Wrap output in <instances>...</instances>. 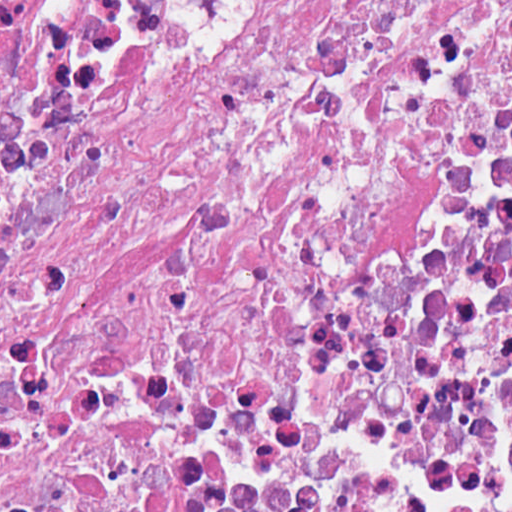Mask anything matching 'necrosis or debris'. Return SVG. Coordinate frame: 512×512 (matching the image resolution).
Segmentation results:
<instances>
[{"label": "necrosis or debris", "mask_w": 512, "mask_h": 512, "mask_svg": "<svg viewBox=\"0 0 512 512\" xmlns=\"http://www.w3.org/2000/svg\"><path fill=\"white\" fill-rule=\"evenodd\" d=\"M0 512H512V1H0Z\"/></svg>", "instance_id": "4bbe7bcc"}]
</instances>
